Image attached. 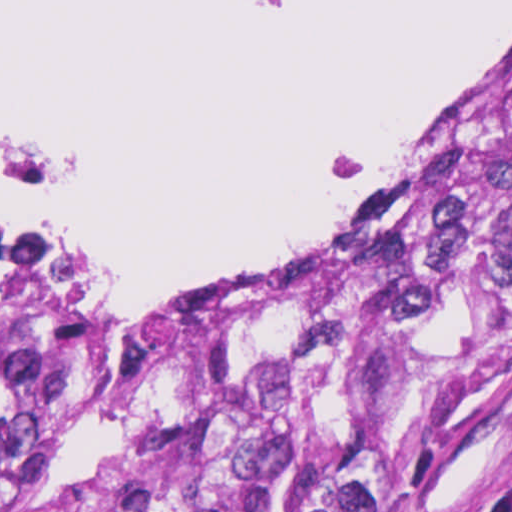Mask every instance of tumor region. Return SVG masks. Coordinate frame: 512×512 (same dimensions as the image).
<instances>
[{
	"instance_id": "1",
	"label": "tumor region",
	"mask_w": 512,
	"mask_h": 512,
	"mask_svg": "<svg viewBox=\"0 0 512 512\" xmlns=\"http://www.w3.org/2000/svg\"><path fill=\"white\" fill-rule=\"evenodd\" d=\"M312 279L26 348L76 289L0 239V512H436L416 373L512 342V46Z\"/></svg>"
}]
</instances>
